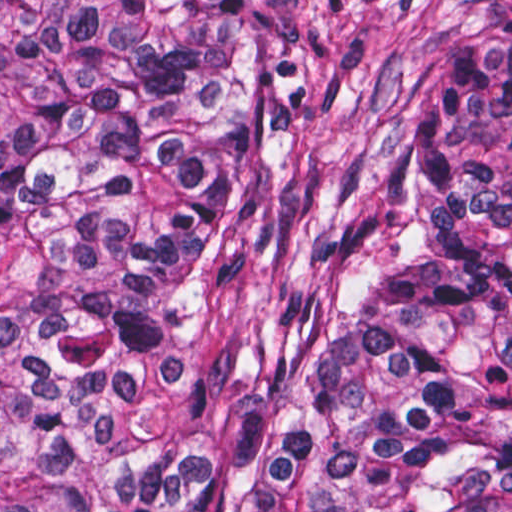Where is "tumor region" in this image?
I'll return each instance as SVG.
<instances>
[{
	"instance_id": "tumor-region-1",
	"label": "tumor region",
	"mask_w": 512,
	"mask_h": 512,
	"mask_svg": "<svg viewBox=\"0 0 512 512\" xmlns=\"http://www.w3.org/2000/svg\"><path fill=\"white\" fill-rule=\"evenodd\" d=\"M0 512H512V0H0Z\"/></svg>"
}]
</instances>
